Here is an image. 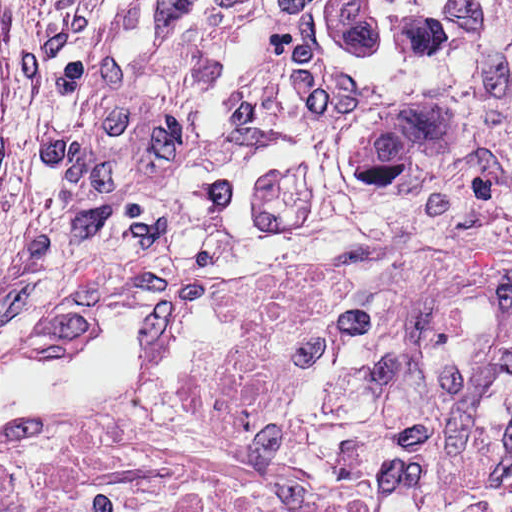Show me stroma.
Masks as SVG:
<instances>
[{
    "mask_svg": "<svg viewBox=\"0 0 512 512\" xmlns=\"http://www.w3.org/2000/svg\"><path fill=\"white\" fill-rule=\"evenodd\" d=\"M239 1L0 0V361L76 367L111 316L150 311L140 386L38 427L158 430L186 463L162 490L0 512H512V214L234 232L86 199L78 149L133 48Z\"/></svg>",
    "mask_w": 512,
    "mask_h": 512,
    "instance_id": "35a3bbf8",
    "label": "stroma"
}]
</instances>
